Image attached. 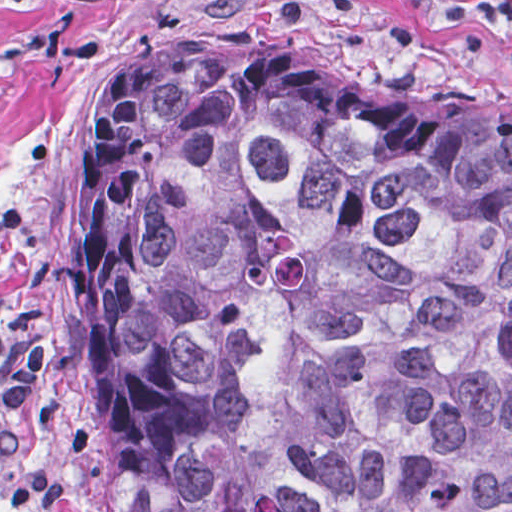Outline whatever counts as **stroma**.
<instances>
[{
  "mask_svg": "<svg viewBox=\"0 0 512 512\" xmlns=\"http://www.w3.org/2000/svg\"><path fill=\"white\" fill-rule=\"evenodd\" d=\"M443 1L512 0H0V512H117L81 215L96 107L115 70L199 29H263L512 120V21H470ZM1 195L17 228L1 227ZM38 334L25 441L1 466V345ZM34 469L62 497L1 504V489Z\"/></svg>",
  "mask_w": 512,
  "mask_h": 512,
  "instance_id": "obj_1",
  "label": "stroma"
}]
</instances>
